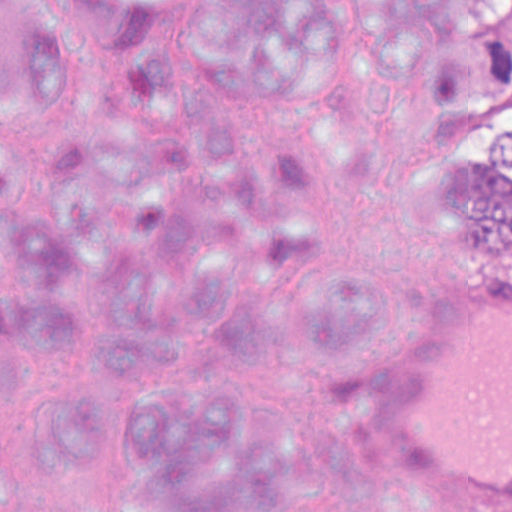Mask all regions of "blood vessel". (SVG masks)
<instances>
[{"instance_id": "obj_1", "label": "blood vessel", "mask_w": 512, "mask_h": 512, "mask_svg": "<svg viewBox=\"0 0 512 512\" xmlns=\"http://www.w3.org/2000/svg\"><path fill=\"white\" fill-rule=\"evenodd\" d=\"M471 413L463 512H512V268L470 272Z\"/></svg>"}]
</instances>
